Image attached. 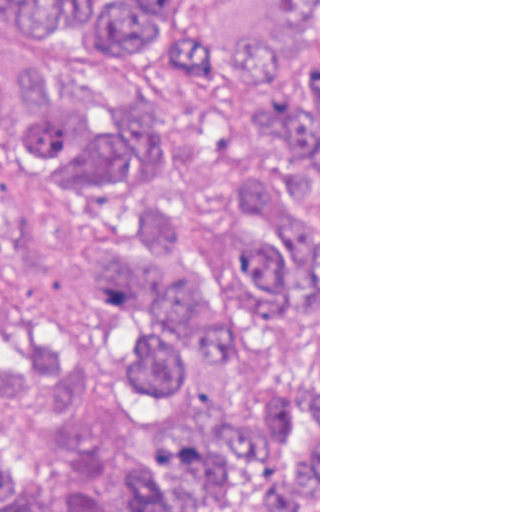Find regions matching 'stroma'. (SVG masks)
Segmentation results:
<instances>
[{"instance_id":"35a3bbf8","label":"stroma","mask_w":512,"mask_h":512,"mask_svg":"<svg viewBox=\"0 0 512 512\" xmlns=\"http://www.w3.org/2000/svg\"><path fill=\"white\" fill-rule=\"evenodd\" d=\"M191 17L219 43L238 47L268 14V0H194ZM34 45L109 90L145 93L158 102L175 132V149L144 192L118 204L82 207L45 170L0 152V222L6 253L16 264L0 328L39 321L69 333L106 338L117 308L96 292L83 262L106 231L123 224L158 193L195 190L209 182V142L186 111L179 61L161 58L134 67H94L50 37L16 26ZM190 339L176 330L174 349ZM51 486V485H50ZM52 491L54 488L51 486ZM318 512H320V0H318Z\"/></svg>"}]
</instances>
